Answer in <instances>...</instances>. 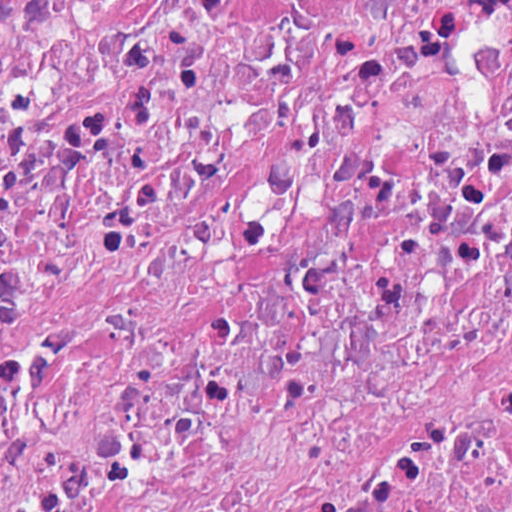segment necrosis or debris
I'll return each instance as SVG.
<instances>
[{
	"instance_id": "4bbe7bcc",
	"label": "necrosis or debris",
	"mask_w": 512,
	"mask_h": 512,
	"mask_svg": "<svg viewBox=\"0 0 512 512\" xmlns=\"http://www.w3.org/2000/svg\"><path fill=\"white\" fill-rule=\"evenodd\" d=\"M0 512H512V0H0Z\"/></svg>"
}]
</instances>
